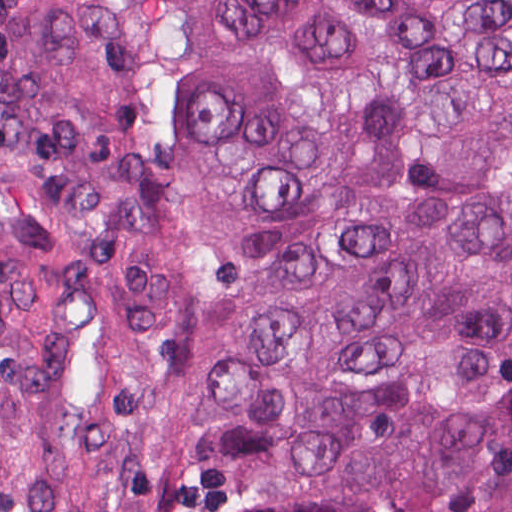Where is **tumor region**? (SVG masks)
Here are the masks:
<instances>
[{"label":"tumor region","instance_id":"1","mask_svg":"<svg viewBox=\"0 0 512 512\" xmlns=\"http://www.w3.org/2000/svg\"><path fill=\"white\" fill-rule=\"evenodd\" d=\"M0 512H512V0H0Z\"/></svg>","mask_w":512,"mask_h":512}]
</instances>
